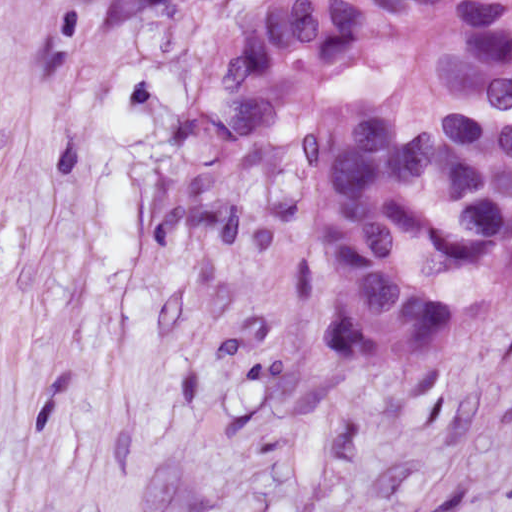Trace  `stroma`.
I'll return each mask as SVG.
<instances>
[{"label": "stroma", "instance_id": "obj_1", "mask_svg": "<svg viewBox=\"0 0 512 512\" xmlns=\"http://www.w3.org/2000/svg\"><path fill=\"white\" fill-rule=\"evenodd\" d=\"M294 1L178 0L42 67L241 512H512V282L445 342L342 375L310 239L245 259L161 216L201 75Z\"/></svg>", "mask_w": 512, "mask_h": 512}]
</instances>
